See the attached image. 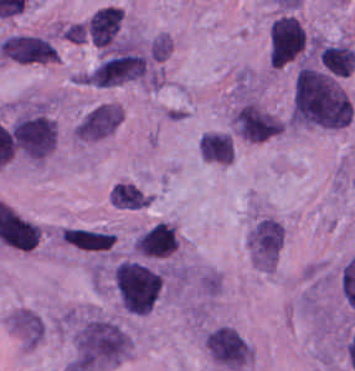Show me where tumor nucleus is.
I'll return each instance as SVG.
<instances>
[{
    "label": "tumor nucleus",
    "mask_w": 355,
    "mask_h": 371,
    "mask_svg": "<svg viewBox=\"0 0 355 371\" xmlns=\"http://www.w3.org/2000/svg\"><path fill=\"white\" fill-rule=\"evenodd\" d=\"M352 114L351 99L339 76L315 67L297 69L287 119L291 126L341 130Z\"/></svg>",
    "instance_id": "1"
},
{
    "label": "tumor nucleus",
    "mask_w": 355,
    "mask_h": 371,
    "mask_svg": "<svg viewBox=\"0 0 355 371\" xmlns=\"http://www.w3.org/2000/svg\"><path fill=\"white\" fill-rule=\"evenodd\" d=\"M75 363L86 371L107 368L127 354L131 340L111 319L97 314H73L70 319Z\"/></svg>",
    "instance_id": "2"
},
{
    "label": "tumor nucleus",
    "mask_w": 355,
    "mask_h": 371,
    "mask_svg": "<svg viewBox=\"0 0 355 371\" xmlns=\"http://www.w3.org/2000/svg\"><path fill=\"white\" fill-rule=\"evenodd\" d=\"M111 280L118 305L135 315H143L157 301L162 272L153 263L123 258L115 263Z\"/></svg>",
    "instance_id": "3"
},
{
    "label": "tumor nucleus",
    "mask_w": 355,
    "mask_h": 371,
    "mask_svg": "<svg viewBox=\"0 0 355 371\" xmlns=\"http://www.w3.org/2000/svg\"><path fill=\"white\" fill-rule=\"evenodd\" d=\"M203 344L216 365L225 371H246L251 362L250 344L230 325H217L204 336Z\"/></svg>",
    "instance_id": "4"
},
{
    "label": "tumor nucleus",
    "mask_w": 355,
    "mask_h": 371,
    "mask_svg": "<svg viewBox=\"0 0 355 371\" xmlns=\"http://www.w3.org/2000/svg\"><path fill=\"white\" fill-rule=\"evenodd\" d=\"M144 62L131 43H123L105 53L91 70V82L97 86H112L137 79Z\"/></svg>",
    "instance_id": "5"
},
{
    "label": "tumor nucleus",
    "mask_w": 355,
    "mask_h": 371,
    "mask_svg": "<svg viewBox=\"0 0 355 371\" xmlns=\"http://www.w3.org/2000/svg\"><path fill=\"white\" fill-rule=\"evenodd\" d=\"M282 242L280 222L266 216L254 222L248 231L251 263L260 270L271 273L277 264Z\"/></svg>",
    "instance_id": "6"
},
{
    "label": "tumor nucleus",
    "mask_w": 355,
    "mask_h": 371,
    "mask_svg": "<svg viewBox=\"0 0 355 371\" xmlns=\"http://www.w3.org/2000/svg\"><path fill=\"white\" fill-rule=\"evenodd\" d=\"M13 138L21 150L33 158H42L56 142V126L39 114H25L12 125Z\"/></svg>",
    "instance_id": "7"
},
{
    "label": "tumor nucleus",
    "mask_w": 355,
    "mask_h": 371,
    "mask_svg": "<svg viewBox=\"0 0 355 371\" xmlns=\"http://www.w3.org/2000/svg\"><path fill=\"white\" fill-rule=\"evenodd\" d=\"M119 124V106L100 103L89 109L73 125L71 133L80 141H88L109 135Z\"/></svg>",
    "instance_id": "8"
},
{
    "label": "tumor nucleus",
    "mask_w": 355,
    "mask_h": 371,
    "mask_svg": "<svg viewBox=\"0 0 355 371\" xmlns=\"http://www.w3.org/2000/svg\"><path fill=\"white\" fill-rule=\"evenodd\" d=\"M137 256L164 259L177 250V232L151 225L136 235Z\"/></svg>",
    "instance_id": "9"
},
{
    "label": "tumor nucleus",
    "mask_w": 355,
    "mask_h": 371,
    "mask_svg": "<svg viewBox=\"0 0 355 371\" xmlns=\"http://www.w3.org/2000/svg\"><path fill=\"white\" fill-rule=\"evenodd\" d=\"M61 234L64 244L89 253H106L115 245V233L103 229L68 227Z\"/></svg>",
    "instance_id": "10"
},
{
    "label": "tumor nucleus",
    "mask_w": 355,
    "mask_h": 371,
    "mask_svg": "<svg viewBox=\"0 0 355 371\" xmlns=\"http://www.w3.org/2000/svg\"><path fill=\"white\" fill-rule=\"evenodd\" d=\"M200 157L217 164L233 161L234 144L225 131H205L198 141Z\"/></svg>",
    "instance_id": "11"
},
{
    "label": "tumor nucleus",
    "mask_w": 355,
    "mask_h": 371,
    "mask_svg": "<svg viewBox=\"0 0 355 371\" xmlns=\"http://www.w3.org/2000/svg\"><path fill=\"white\" fill-rule=\"evenodd\" d=\"M322 65L338 76H348L355 65V52L344 44H331L321 49Z\"/></svg>",
    "instance_id": "12"
},
{
    "label": "tumor nucleus",
    "mask_w": 355,
    "mask_h": 371,
    "mask_svg": "<svg viewBox=\"0 0 355 371\" xmlns=\"http://www.w3.org/2000/svg\"><path fill=\"white\" fill-rule=\"evenodd\" d=\"M109 199L116 209L139 210L144 205V193L126 181H118L111 187Z\"/></svg>",
    "instance_id": "13"
}]
</instances>
